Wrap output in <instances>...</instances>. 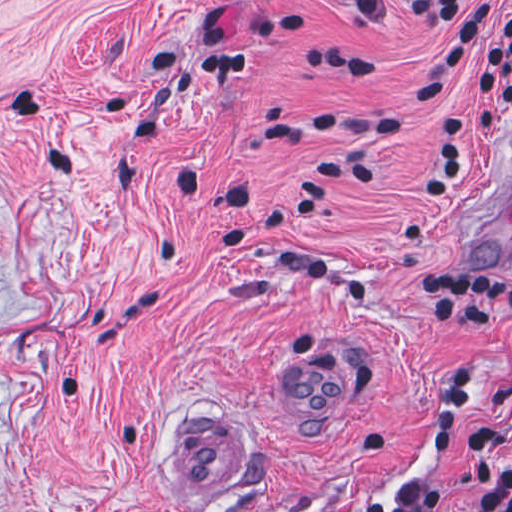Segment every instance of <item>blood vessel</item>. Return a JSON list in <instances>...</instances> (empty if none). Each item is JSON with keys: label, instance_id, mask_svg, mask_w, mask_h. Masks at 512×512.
Here are the masks:
<instances>
[{"label": "blood vessel", "instance_id": "1", "mask_svg": "<svg viewBox=\"0 0 512 512\" xmlns=\"http://www.w3.org/2000/svg\"><path fill=\"white\" fill-rule=\"evenodd\" d=\"M512 243V134L481 165L459 198L447 249L482 262ZM278 395L300 432H333L359 399V369L342 349L300 339L281 355ZM206 405L178 413L163 450V470L179 502H220L236 425Z\"/></svg>", "mask_w": 512, "mask_h": 512}]
</instances>
